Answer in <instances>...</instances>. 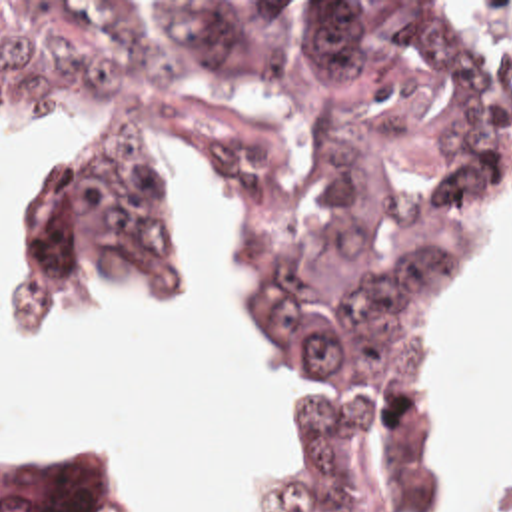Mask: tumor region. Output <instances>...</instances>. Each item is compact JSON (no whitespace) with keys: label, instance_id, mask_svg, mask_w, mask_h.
<instances>
[{"label":"tumor region","instance_id":"tumor-region-1","mask_svg":"<svg viewBox=\"0 0 512 512\" xmlns=\"http://www.w3.org/2000/svg\"><path fill=\"white\" fill-rule=\"evenodd\" d=\"M0 108L98 116L0 283L2 321L166 272V152H194L299 385L283 509H453L435 345L512 248V2H0ZM0 512L122 505L106 473L0 459Z\"/></svg>","mask_w":512,"mask_h":512}]
</instances>
